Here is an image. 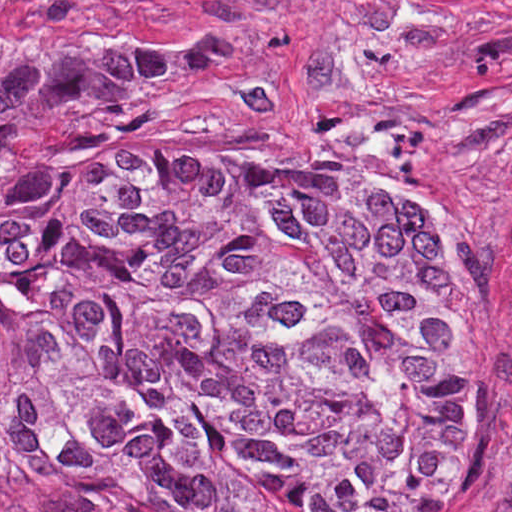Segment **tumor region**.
<instances>
[{"instance_id": "obj_1", "label": "tumor region", "mask_w": 512, "mask_h": 512, "mask_svg": "<svg viewBox=\"0 0 512 512\" xmlns=\"http://www.w3.org/2000/svg\"><path fill=\"white\" fill-rule=\"evenodd\" d=\"M311 44L287 13L179 46L0 33V476L341 512L455 484L457 309L401 265L468 224L316 159L182 154Z\"/></svg>"}]
</instances>
